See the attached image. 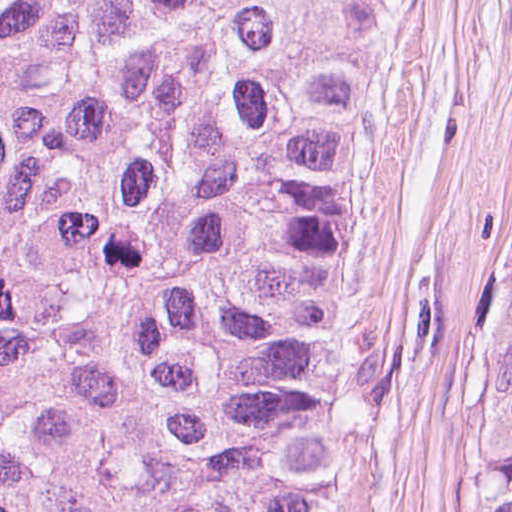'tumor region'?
<instances>
[{
    "mask_svg": "<svg viewBox=\"0 0 512 512\" xmlns=\"http://www.w3.org/2000/svg\"><path fill=\"white\" fill-rule=\"evenodd\" d=\"M370 3L0 0V512H332L327 313ZM482 512H512V302Z\"/></svg>",
    "mask_w": 512,
    "mask_h": 512,
    "instance_id": "e687c5a6",
    "label": "tumor region"
}]
</instances>
